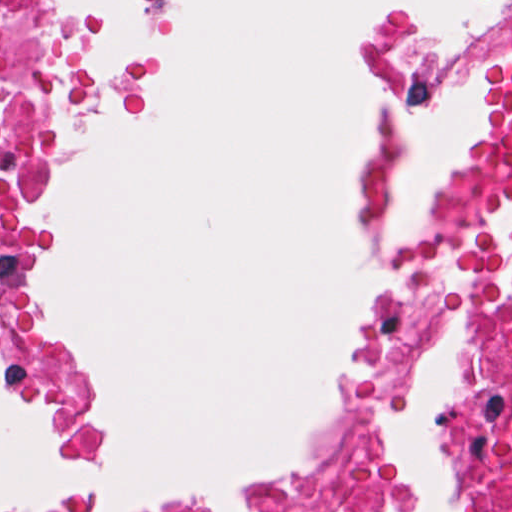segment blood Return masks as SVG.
Instances as JSON below:
<instances>
[{"label":"blood","instance_id":"blood-1","mask_svg":"<svg viewBox=\"0 0 512 512\" xmlns=\"http://www.w3.org/2000/svg\"><path fill=\"white\" fill-rule=\"evenodd\" d=\"M508 188H512V61L479 128L454 162L437 221Z\"/></svg>","mask_w":512,"mask_h":512}]
</instances>
